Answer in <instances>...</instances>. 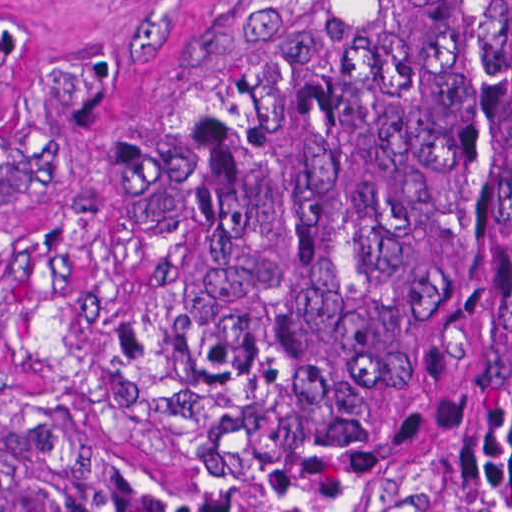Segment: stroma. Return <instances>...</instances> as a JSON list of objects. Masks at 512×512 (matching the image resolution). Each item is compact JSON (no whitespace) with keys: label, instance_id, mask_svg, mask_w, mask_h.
Masks as SVG:
<instances>
[{"label":"stroma","instance_id":"obj_1","mask_svg":"<svg viewBox=\"0 0 512 512\" xmlns=\"http://www.w3.org/2000/svg\"><path fill=\"white\" fill-rule=\"evenodd\" d=\"M281 0H18L0 132L47 85L73 93L85 149L0 199V400L88 423L184 512H367L267 448L218 432L156 261L117 222L102 146L142 130Z\"/></svg>","mask_w":512,"mask_h":512}]
</instances>
